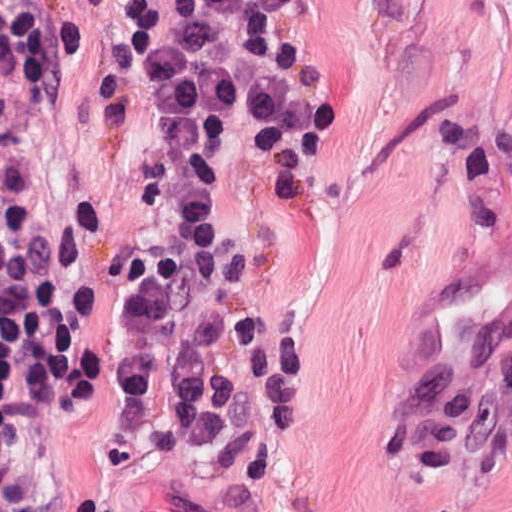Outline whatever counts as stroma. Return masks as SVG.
<instances>
[{
    "label": "stroma",
    "instance_id": "1",
    "mask_svg": "<svg viewBox=\"0 0 512 512\" xmlns=\"http://www.w3.org/2000/svg\"><path fill=\"white\" fill-rule=\"evenodd\" d=\"M132 0H0V130L43 170L83 255L98 356L157 183ZM326 123L294 191L267 129L228 221L296 288L310 357L235 458L134 439L98 386L45 429L70 512H512V437L432 469L371 434L435 365L512 317V0H320Z\"/></svg>",
    "mask_w": 512,
    "mask_h": 512
}]
</instances>
